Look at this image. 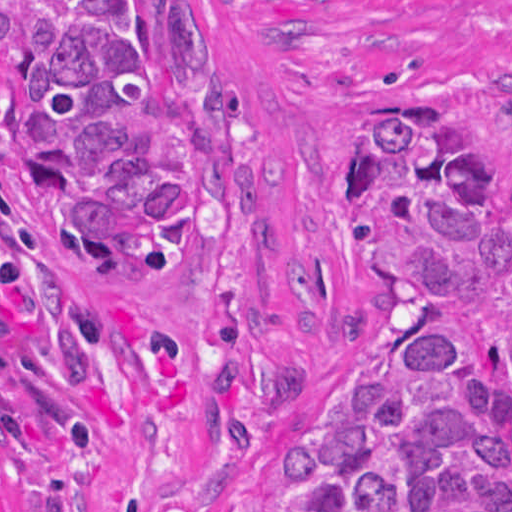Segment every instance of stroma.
Returning a JSON list of instances; mask_svg holds the SVG:
<instances>
[{"label":"stroma","mask_w":512,"mask_h":512,"mask_svg":"<svg viewBox=\"0 0 512 512\" xmlns=\"http://www.w3.org/2000/svg\"><path fill=\"white\" fill-rule=\"evenodd\" d=\"M215 80L213 231L193 270H120L125 447L71 512H266L295 432L363 361L373 279L345 198L402 107L478 161L512 134V0H191ZM11 512H51L13 465Z\"/></svg>","instance_id":"35a3bbf8"}]
</instances>
